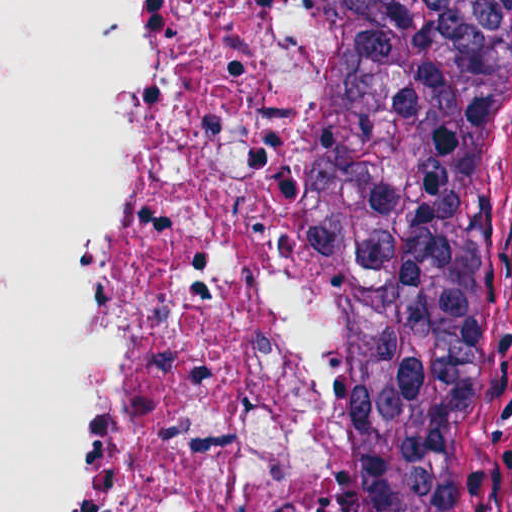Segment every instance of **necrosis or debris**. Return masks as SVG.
Segmentation results:
<instances>
[{
	"instance_id": "necrosis-or-debris-1",
	"label": "necrosis or debris",
	"mask_w": 512,
	"mask_h": 512,
	"mask_svg": "<svg viewBox=\"0 0 512 512\" xmlns=\"http://www.w3.org/2000/svg\"><path fill=\"white\" fill-rule=\"evenodd\" d=\"M134 111L97 512H312L302 0H114Z\"/></svg>"
}]
</instances>
